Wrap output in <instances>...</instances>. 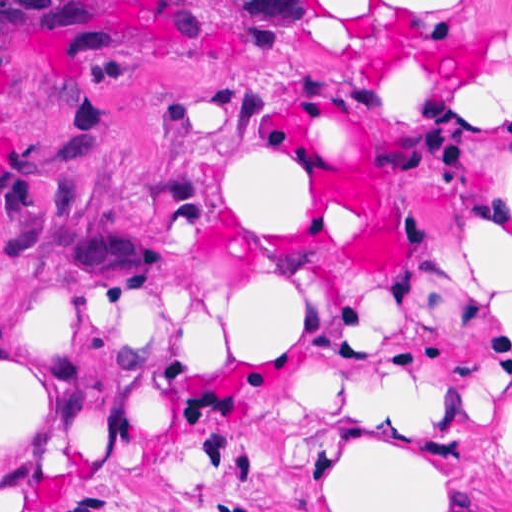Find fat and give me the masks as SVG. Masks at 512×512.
<instances>
[{"label": "fat", "instance_id": "1", "mask_svg": "<svg viewBox=\"0 0 512 512\" xmlns=\"http://www.w3.org/2000/svg\"><path fill=\"white\" fill-rule=\"evenodd\" d=\"M384 57L458 75L512 101V54L489 82L512 1H328ZM245 164L236 218L299 247L304 187ZM456 252L512 330V107L450 122ZM183 308H88L0 282V512L37 505L86 468L165 450L276 407H361L480 444L512 466V400L498 403L493 345L469 327L368 339L328 327L315 265L286 248L223 261ZM205 291V292H206ZM448 483L349 431L321 449L316 512H438Z\"/></svg>", "mask_w": 512, "mask_h": 512}]
</instances>
